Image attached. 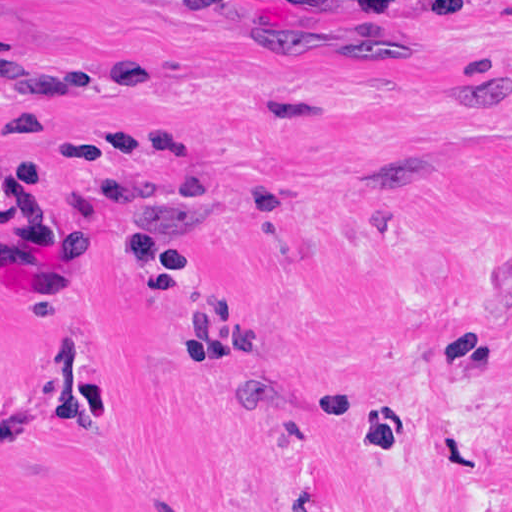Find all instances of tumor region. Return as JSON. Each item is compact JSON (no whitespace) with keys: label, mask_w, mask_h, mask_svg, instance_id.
Masks as SVG:
<instances>
[{"label":"tumor region","mask_w":512,"mask_h":512,"mask_svg":"<svg viewBox=\"0 0 512 512\" xmlns=\"http://www.w3.org/2000/svg\"><path fill=\"white\" fill-rule=\"evenodd\" d=\"M292 11L328 18H361L366 0H266Z\"/></svg>","instance_id":"e687c5a6"}]
</instances>
